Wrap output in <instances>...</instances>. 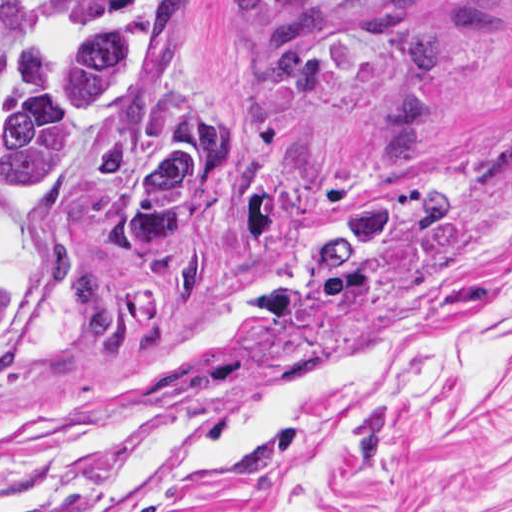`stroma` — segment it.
<instances>
[{
  "label": "stroma",
  "mask_w": 512,
  "mask_h": 512,
  "mask_svg": "<svg viewBox=\"0 0 512 512\" xmlns=\"http://www.w3.org/2000/svg\"><path fill=\"white\" fill-rule=\"evenodd\" d=\"M243 0H189L157 84L96 147L220 106ZM84 0H4L0 81L95 20ZM24 326L0 357V439L90 427L134 399L212 417L364 344L512 331V0H362L318 47L279 135L201 261L132 286L76 239L7 221ZM326 493L364 512H512V419L477 394L363 398L329 423ZM244 473L203 470L104 510L235 512Z\"/></svg>",
  "instance_id": "1"
}]
</instances>
